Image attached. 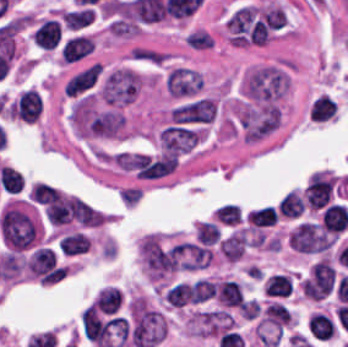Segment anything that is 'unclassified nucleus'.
Returning <instances> with one entry per match:
<instances>
[{
  "instance_id": "0b8be0a9",
  "label": "unclassified nucleus",
  "mask_w": 348,
  "mask_h": 347,
  "mask_svg": "<svg viewBox=\"0 0 348 347\" xmlns=\"http://www.w3.org/2000/svg\"><path fill=\"white\" fill-rule=\"evenodd\" d=\"M289 81L283 69L263 66L251 69L243 80L244 97L256 105L276 102L286 93Z\"/></svg>"
},
{
  "instance_id": "b2318f4d",
  "label": "unclassified nucleus",
  "mask_w": 348,
  "mask_h": 347,
  "mask_svg": "<svg viewBox=\"0 0 348 347\" xmlns=\"http://www.w3.org/2000/svg\"><path fill=\"white\" fill-rule=\"evenodd\" d=\"M217 113L213 99L193 96L177 103L169 112L173 126L201 127L214 121Z\"/></svg>"
},
{
  "instance_id": "928a53df",
  "label": "unclassified nucleus",
  "mask_w": 348,
  "mask_h": 347,
  "mask_svg": "<svg viewBox=\"0 0 348 347\" xmlns=\"http://www.w3.org/2000/svg\"><path fill=\"white\" fill-rule=\"evenodd\" d=\"M140 76L126 68L115 69L106 79L101 93L110 104L128 103L136 95Z\"/></svg>"
},
{
  "instance_id": "975e440c",
  "label": "unclassified nucleus",
  "mask_w": 348,
  "mask_h": 347,
  "mask_svg": "<svg viewBox=\"0 0 348 347\" xmlns=\"http://www.w3.org/2000/svg\"><path fill=\"white\" fill-rule=\"evenodd\" d=\"M200 85L197 70L191 68H171L165 77V86L173 96H196Z\"/></svg>"
}]
</instances>
